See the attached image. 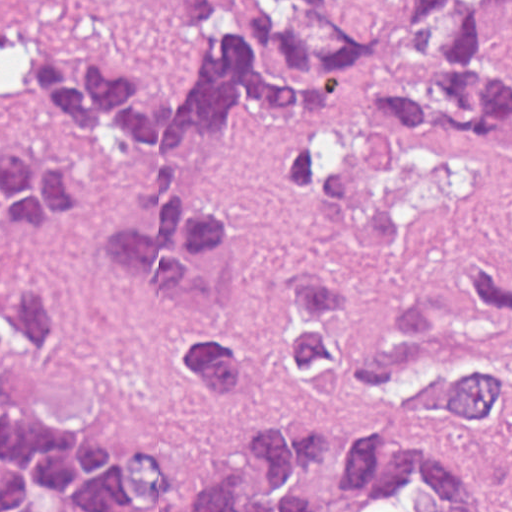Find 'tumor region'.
Here are the masks:
<instances>
[{
  "label": "tumor region",
  "instance_id": "1",
  "mask_svg": "<svg viewBox=\"0 0 512 512\" xmlns=\"http://www.w3.org/2000/svg\"><path fill=\"white\" fill-rule=\"evenodd\" d=\"M512 0H409L400 30L365 42L326 0H262L238 22L220 0H166L183 37L202 48L179 93L135 67L76 70L50 48H17L38 116L156 151L162 171L137 186L147 229L114 236L119 270L151 282L175 325L172 363L190 389L245 400L257 381L248 339L222 323V289L244 247L239 215L192 199L186 146L218 134L240 107L282 117L315 111V128L280 140L270 191L299 204L325 176L331 192L308 237L390 252L397 215L352 165L339 119L344 80L369 90L375 120L423 146L512 151V72L493 47L495 14ZM92 183L67 165L0 139V241L68 219ZM75 313L62 281L0 265V372L53 345ZM281 354L307 402L498 432L512 442V275L477 255L438 267V291L406 312H367L330 276L305 268L281 296ZM330 435L301 415L248 428V476L219 463L180 503L167 465L140 447H103L0 402V512H322L310 480ZM340 472L355 512H501L485 479L408 441L355 435Z\"/></svg>",
  "mask_w": 512,
  "mask_h": 512
}]
</instances>
